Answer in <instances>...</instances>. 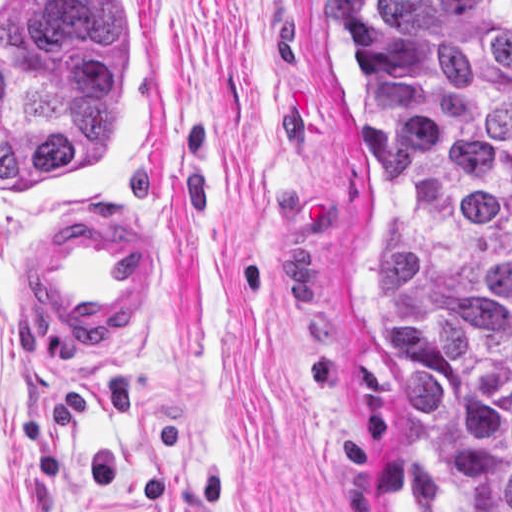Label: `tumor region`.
I'll return each mask as SVG.
<instances>
[{"label":"tumor region","mask_w":512,"mask_h":512,"mask_svg":"<svg viewBox=\"0 0 512 512\" xmlns=\"http://www.w3.org/2000/svg\"><path fill=\"white\" fill-rule=\"evenodd\" d=\"M387 191L379 339L427 512H512V1H337Z\"/></svg>","instance_id":"tumor-region-1"}]
</instances>
